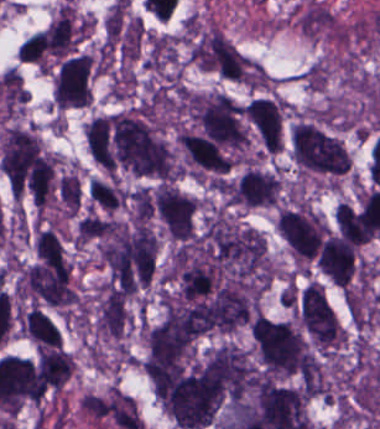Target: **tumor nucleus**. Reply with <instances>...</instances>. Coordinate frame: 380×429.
<instances>
[{
  "mask_svg": "<svg viewBox=\"0 0 380 429\" xmlns=\"http://www.w3.org/2000/svg\"><path fill=\"white\" fill-rule=\"evenodd\" d=\"M289 138L292 157L303 170L337 175L350 165V153L341 136L316 120L298 118Z\"/></svg>",
  "mask_w": 380,
  "mask_h": 429,
  "instance_id": "tumor-nucleus-3",
  "label": "tumor nucleus"
},
{
  "mask_svg": "<svg viewBox=\"0 0 380 429\" xmlns=\"http://www.w3.org/2000/svg\"><path fill=\"white\" fill-rule=\"evenodd\" d=\"M189 59L221 77L236 81L247 78L246 58L218 27H199L193 31Z\"/></svg>",
  "mask_w": 380,
  "mask_h": 429,
  "instance_id": "tumor-nucleus-5",
  "label": "tumor nucleus"
},
{
  "mask_svg": "<svg viewBox=\"0 0 380 429\" xmlns=\"http://www.w3.org/2000/svg\"><path fill=\"white\" fill-rule=\"evenodd\" d=\"M274 228L295 259L303 262H314L329 230L306 202L298 200L277 213Z\"/></svg>",
  "mask_w": 380,
  "mask_h": 429,
  "instance_id": "tumor-nucleus-4",
  "label": "tumor nucleus"
},
{
  "mask_svg": "<svg viewBox=\"0 0 380 429\" xmlns=\"http://www.w3.org/2000/svg\"><path fill=\"white\" fill-rule=\"evenodd\" d=\"M252 342L262 372L272 377H305L306 344L298 326L256 315L251 320Z\"/></svg>",
  "mask_w": 380,
  "mask_h": 429,
  "instance_id": "tumor-nucleus-2",
  "label": "tumor nucleus"
},
{
  "mask_svg": "<svg viewBox=\"0 0 380 429\" xmlns=\"http://www.w3.org/2000/svg\"><path fill=\"white\" fill-rule=\"evenodd\" d=\"M93 78L91 58L83 54L64 57L55 69L53 107L70 109L91 104Z\"/></svg>",
  "mask_w": 380,
  "mask_h": 429,
  "instance_id": "tumor-nucleus-6",
  "label": "tumor nucleus"
},
{
  "mask_svg": "<svg viewBox=\"0 0 380 429\" xmlns=\"http://www.w3.org/2000/svg\"><path fill=\"white\" fill-rule=\"evenodd\" d=\"M129 322L127 297L122 293L102 289L96 303L95 330L102 337L119 339Z\"/></svg>",
  "mask_w": 380,
  "mask_h": 429,
  "instance_id": "tumor-nucleus-10",
  "label": "tumor nucleus"
},
{
  "mask_svg": "<svg viewBox=\"0 0 380 429\" xmlns=\"http://www.w3.org/2000/svg\"><path fill=\"white\" fill-rule=\"evenodd\" d=\"M23 330L36 345H62L56 324L40 308L27 311Z\"/></svg>",
  "mask_w": 380,
  "mask_h": 429,
  "instance_id": "tumor-nucleus-11",
  "label": "tumor nucleus"
},
{
  "mask_svg": "<svg viewBox=\"0 0 380 429\" xmlns=\"http://www.w3.org/2000/svg\"><path fill=\"white\" fill-rule=\"evenodd\" d=\"M157 217L167 235L185 242L193 237L196 227L197 200L168 182L155 186Z\"/></svg>",
  "mask_w": 380,
  "mask_h": 429,
  "instance_id": "tumor-nucleus-7",
  "label": "tumor nucleus"
},
{
  "mask_svg": "<svg viewBox=\"0 0 380 429\" xmlns=\"http://www.w3.org/2000/svg\"><path fill=\"white\" fill-rule=\"evenodd\" d=\"M298 311L304 331L322 343H336L337 331L333 310L324 288L308 282L298 297Z\"/></svg>",
  "mask_w": 380,
  "mask_h": 429,
  "instance_id": "tumor-nucleus-9",
  "label": "tumor nucleus"
},
{
  "mask_svg": "<svg viewBox=\"0 0 380 429\" xmlns=\"http://www.w3.org/2000/svg\"><path fill=\"white\" fill-rule=\"evenodd\" d=\"M146 373L162 411L180 428L210 426L233 379L230 344L148 355Z\"/></svg>",
  "mask_w": 380,
  "mask_h": 429,
  "instance_id": "tumor-nucleus-1",
  "label": "tumor nucleus"
},
{
  "mask_svg": "<svg viewBox=\"0 0 380 429\" xmlns=\"http://www.w3.org/2000/svg\"><path fill=\"white\" fill-rule=\"evenodd\" d=\"M282 187L283 181L275 170L251 164L232 181L231 203L245 208L274 206Z\"/></svg>",
  "mask_w": 380,
  "mask_h": 429,
  "instance_id": "tumor-nucleus-8",
  "label": "tumor nucleus"
}]
</instances>
